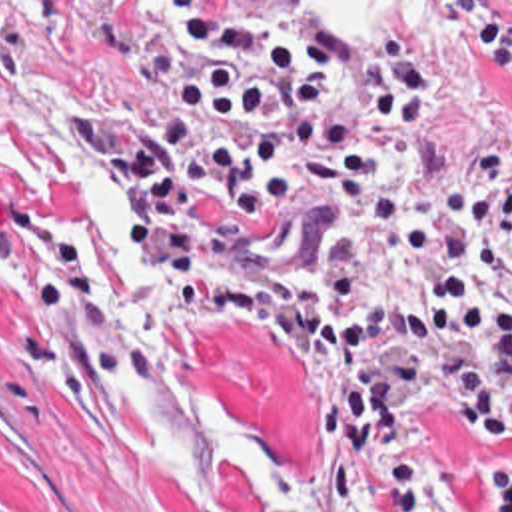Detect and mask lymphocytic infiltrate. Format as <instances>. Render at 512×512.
Wrapping results in <instances>:
<instances>
[{"mask_svg": "<svg viewBox=\"0 0 512 512\" xmlns=\"http://www.w3.org/2000/svg\"><path fill=\"white\" fill-rule=\"evenodd\" d=\"M510 0H444L450 26L512 94ZM197 48L143 158L129 116L87 122L117 168L137 232L175 316L257 336L281 382L305 394L326 479L368 512H430L432 462L408 444L412 416L450 410L480 448L508 444L512 300L478 272L388 310L356 292L438 248L434 224L402 214L380 258H295L277 226L291 190L390 184L416 138L440 134L448 92L436 66L394 36L344 40L318 26L231 14L223 0H163ZM494 495L472 512H510L506 454L482 463Z\"/></svg>", "mask_w": 512, "mask_h": 512, "instance_id": "lymphocytic-infiltrate-1", "label": "lymphocytic infiltrate"}]
</instances>
